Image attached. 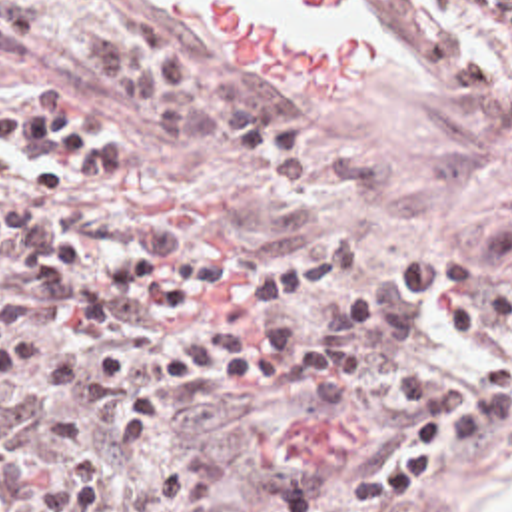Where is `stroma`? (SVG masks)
Segmentation results:
<instances>
[{
  "instance_id": "stroma-1",
  "label": "stroma",
  "mask_w": 512,
  "mask_h": 512,
  "mask_svg": "<svg viewBox=\"0 0 512 512\" xmlns=\"http://www.w3.org/2000/svg\"><path fill=\"white\" fill-rule=\"evenodd\" d=\"M287 26L376 42V70L342 86H269L225 70L209 28L177 0H0V106L109 122L125 174L163 198L179 226L309 261L338 236L402 254H464L512 198V36L462 0H354L322 16L247 0ZM145 12L197 66L259 100L318 148V180L293 194H243L227 162L187 152L105 108L75 44L119 14ZM444 512H512V463L452 473Z\"/></svg>"
}]
</instances>
